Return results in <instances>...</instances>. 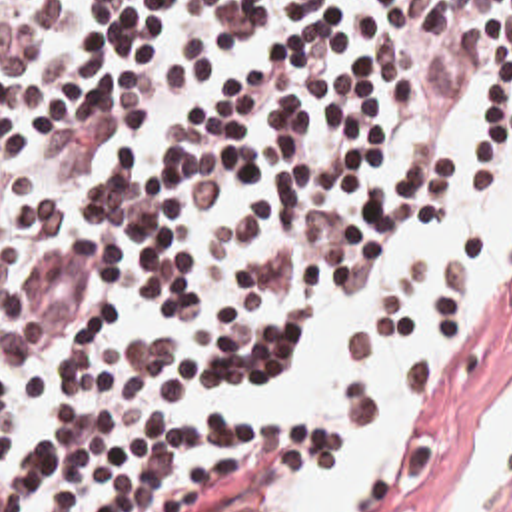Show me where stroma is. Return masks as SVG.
<instances>
[{
	"label": "stroma",
	"instance_id": "35a3bbf8",
	"mask_svg": "<svg viewBox=\"0 0 512 512\" xmlns=\"http://www.w3.org/2000/svg\"><path fill=\"white\" fill-rule=\"evenodd\" d=\"M377 348L387 346H357L349 356ZM511 386L512 290L483 330L463 340L427 398L403 482L383 512H447L481 422ZM245 390L267 420L293 428L263 404V388ZM501 512H512V492Z\"/></svg>",
	"mask_w": 512,
	"mask_h": 512
}]
</instances>
